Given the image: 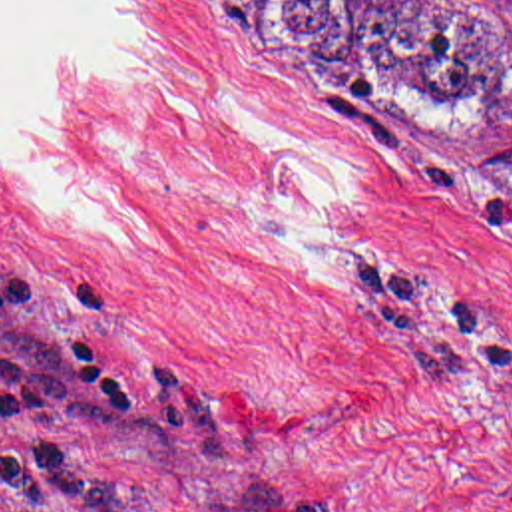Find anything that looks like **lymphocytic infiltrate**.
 Instances as JSON below:
<instances>
[{"label": "lymphocytic infiltrate", "mask_w": 512, "mask_h": 512, "mask_svg": "<svg viewBox=\"0 0 512 512\" xmlns=\"http://www.w3.org/2000/svg\"><path fill=\"white\" fill-rule=\"evenodd\" d=\"M0 322L37 328L83 352L106 372L130 380V344L116 324L89 306L0 280Z\"/></svg>", "instance_id": "1"}]
</instances>
